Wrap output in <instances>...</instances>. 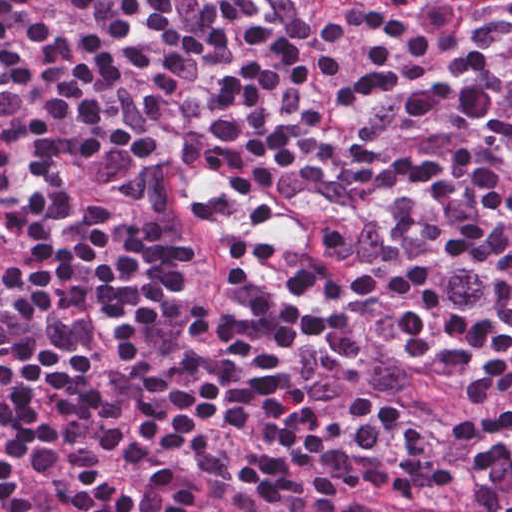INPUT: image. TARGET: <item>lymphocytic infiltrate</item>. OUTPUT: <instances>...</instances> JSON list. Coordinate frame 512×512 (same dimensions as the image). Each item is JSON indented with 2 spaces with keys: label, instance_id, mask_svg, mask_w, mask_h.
Segmentation results:
<instances>
[{
  "label": "lymphocytic infiltrate",
  "instance_id": "f902f5d3",
  "mask_svg": "<svg viewBox=\"0 0 512 512\" xmlns=\"http://www.w3.org/2000/svg\"><path fill=\"white\" fill-rule=\"evenodd\" d=\"M471 0H0V512Z\"/></svg>",
  "mask_w": 512,
  "mask_h": 512
}]
</instances>
